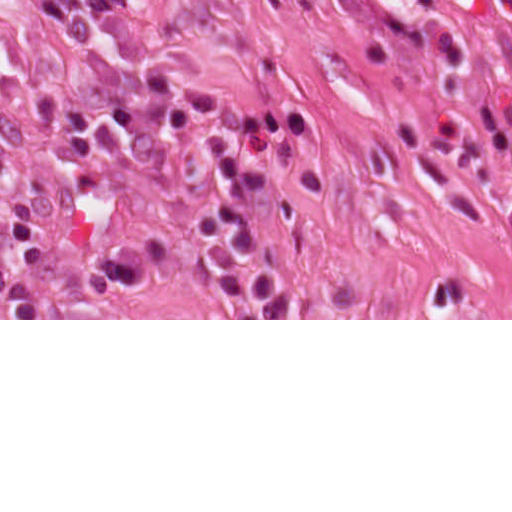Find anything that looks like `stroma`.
Returning <instances> with one entry per match:
<instances>
[{
  "mask_svg": "<svg viewBox=\"0 0 512 512\" xmlns=\"http://www.w3.org/2000/svg\"><path fill=\"white\" fill-rule=\"evenodd\" d=\"M188 88L309 120L246 204L289 319H233L194 249L221 186L215 129L165 133ZM0 160L57 300L0 320H512V0H0ZM128 243L139 287L89 295Z\"/></svg>",
  "mask_w": 512,
  "mask_h": 512,
  "instance_id": "obj_1",
  "label": "stroma"
}]
</instances>
